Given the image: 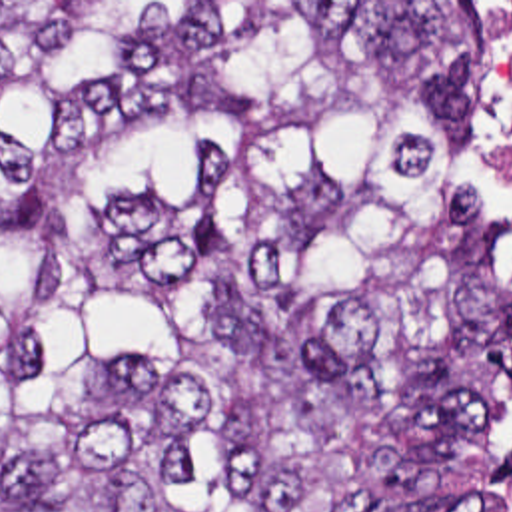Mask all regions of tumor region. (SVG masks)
<instances>
[{"label": "tumor region", "instance_id": "obj_1", "mask_svg": "<svg viewBox=\"0 0 512 512\" xmlns=\"http://www.w3.org/2000/svg\"><path fill=\"white\" fill-rule=\"evenodd\" d=\"M471 2H0V512H512Z\"/></svg>", "mask_w": 512, "mask_h": 512}]
</instances>
